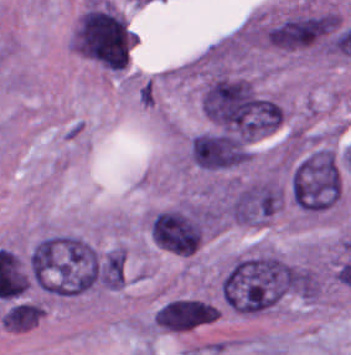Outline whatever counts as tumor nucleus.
Masks as SVG:
<instances>
[{
    "instance_id": "tumor-nucleus-4",
    "label": "tumor nucleus",
    "mask_w": 351,
    "mask_h": 355,
    "mask_svg": "<svg viewBox=\"0 0 351 355\" xmlns=\"http://www.w3.org/2000/svg\"><path fill=\"white\" fill-rule=\"evenodd\" d=\"M264 43L289 51L324 50L328 38V18L323 11L300 10L265 23Z\"/></svg>"
},
{
    "instance_id": "tumor-nucleus-6",
    "label": "tumor nucleus",
    "mask_w": 351,
    "mask_h": 355,
    "mask_svg": "<svg viewBox=\"0 0 351 355\" xmlns=\"http://www.w3.org/2000/svg\"><path fill=\"white\" fill-rule=\"evenodd\" d=\"M277 207L276 181L261 177L235 181L225 193L223 214L229 221L262 224Z\"/></svg>"
},
{
    "instance_id": "tumor-nucleus-2",
    "label": "tumor nucleus",
    "mask_w": 351,
    "mask_h": 355,
    "mask_svg": "<svg viewBox=\"0 0 351 355\" xmlns=\"http://www.w3.org/2000/svg\"><path fill=\"white\" fill-rule=\"evenodd\" d=\"M133 39L128 21L117 8L96 0L79 15L70 44L90 58H129Z\"/></svg>"
},
{
    "instance_id": "tumor-nucleus-3",
    "label": "tumor nucleus",
    "mask_w": 351,
    "mask_h": 355,
    "mask_svg": "<svg viewBox=\"0 0 351 355\" xmlns=\"http://www.w3.org/2000/svg\"><path fill=\"white\" fill-rule=\"evenodd\" d=\"M210 220V209L206 207H174L152 212L147 228L164 251L190 254L199 247Z\"/></svg>"
},
{
    "instance_id": "tumor-nucleus-7",
    "label": "tumor nucleus",
    "mask_w": 351,
    "mask_h": 355,
    "mask_svg": "<svg viewBox=\"0 0 351 355\" xmlns=\"http://www.w3.org/2000/svg\"><path fill=\"white\" fill-rule=\"evenodd\" d=\"M44 310L42 303L35 299H15L4 308L0 321L11 329H27L39 320Z\"/></svg>"
},
{
    "instance_id": "tumor-nucleus-1",
    "label": "tumor nucleus",
    "mask_w": 351,
    "mask_h": 355,
    "mask_svg": "<svg viewBox=\"0 0 351 355\" xmlns=\"http://www.w3.org/2000/svg\"><path fill=\"white\" fill-rule=\"evenodd\" d=\"M287 189L299 211L312 216L323 213L341 192L336 154L329 146L300 144L290 161Z\"/></svg>"
},
{
    "instance_id": "tumor-nucleus-5",
    "label": "tumor nucleus",
    "mask_w": 351,
    "mask_h": 355,
    "mask_svg": "<svg viewBox=\"0 0 351 355\" xmlns=\"http://www.w3.org/2000/svg\"><path fill=\"white\" fill-rule=\"evenodd\" d=\"M252 139L220 129L198 131L189 143V159L209 171L234 169L249 161Z\"/></svg>"
}]
</instances>
